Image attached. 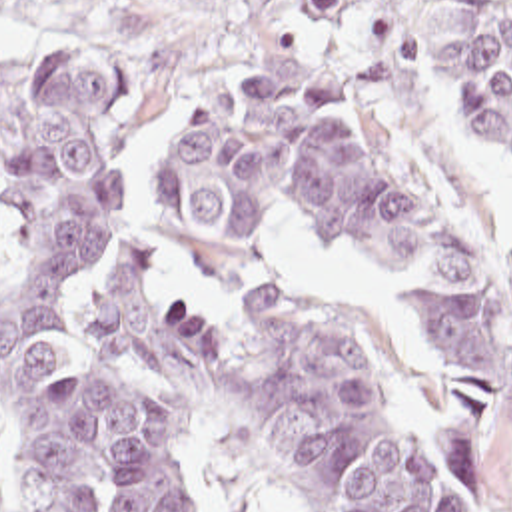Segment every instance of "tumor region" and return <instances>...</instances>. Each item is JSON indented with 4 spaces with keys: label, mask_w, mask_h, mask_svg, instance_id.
Returning <instances> with one entry per match:
<instances>
[{
    "label": "tumor region",
    "mask_w": 512,
    "mask_h": 512,
    "mask_svg": "<svg viewBox=\"0 0 512 512\" xmlns=\"http://www.w3.org/2000/svg\"><path fill=\"white\" fill-rule=\"evenodd\" d=\"M12 0H0V6ZM330 56L346 94L413 76V0H260ZM441 124L512 148V2L429 20ZM118 70L0 60V414L30 512L206 509L148 384L228 404L308 512H455L350 332L284 302L260 224L294 208L388 266L463 394L512 452V290L465 212L364 106L276 76L198 98L156 182L162 244L120 246L88 328L74 266L116 200Z\"/></svg>",
    "instance_id": "tumor-region-1"
}]
</instances>
